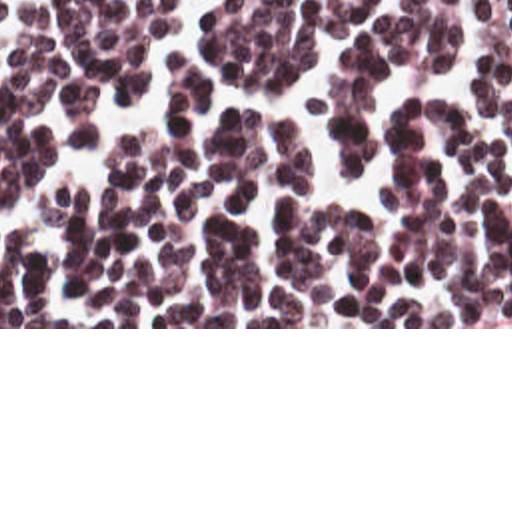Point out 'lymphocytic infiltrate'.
<instances>
[{
  "label": "lymphocytic infiltrate",
  "mask_w": 512,
  "mask_h": 512,
  "mask_svg": "<svg viewBox=\"0 0 512 512\" xmlns=\"http://www.w3.org/2000/svg\"><path fill=\"white\" fill-rule=\"evenodd\" d=\"M180 0H0V215L34 197L58 155L42 129L72 113L100 145L110 107L140 101ZM346 36L308 99L342 167L372 161L384 77L448 75L456 0H222L210 49L232 85L290 81L322 34ZM479 69L495 111L444 93L398 107L382 199L316 203L302 123L222 111L202 133L208 75L176 57L168 125L128 137L110 179L62 185L50 255L0 243V327H512V0H489Z\"/></svg>",
  "instance_id": "1"
}]
</instances>
